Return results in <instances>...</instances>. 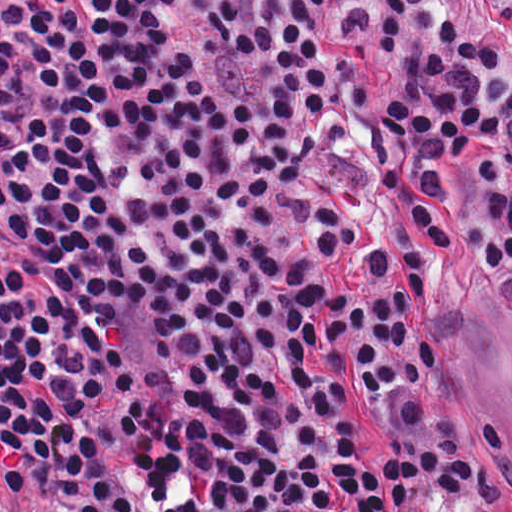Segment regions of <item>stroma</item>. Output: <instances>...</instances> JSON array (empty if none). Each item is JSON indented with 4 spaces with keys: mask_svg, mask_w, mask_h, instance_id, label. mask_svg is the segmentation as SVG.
<instances>
[{
    "mask_svg": "<svg viewBox=\"0 0 512 512\" xmlns=\"http://www.w3.org/2000/svg\"><path fill=\"white\" fill-rule=\"evenodd\" d=\"M436 12L490 40L512 68V21L495 16L486 0H440ZM429 284L454 339L430 401L459 418L498 419L504 430L498 490L466 512H512V266L450 264Z\"/></svg>",
    "mask_w": 512,
    "mask_h": 512,
    "instance_id": "35a3bbf8",
    "label": "stroma"
}]
</instances>
